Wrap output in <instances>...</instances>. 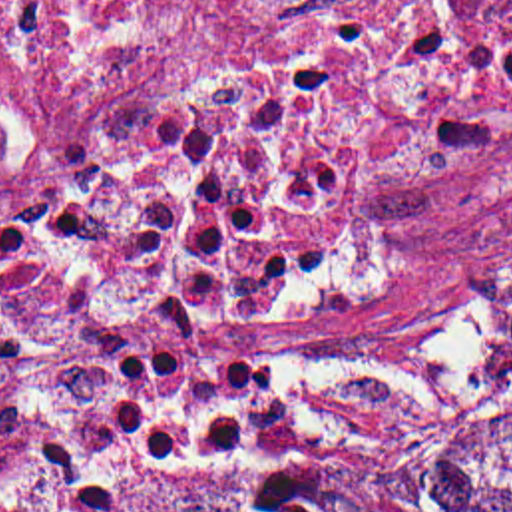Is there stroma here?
Returning <instances> with one entry per match:
<instances>
[{"label":"stroma","instance_id":"35a3bbf8","mask_svg":"<svg viewBox=\"0 0 512 512\" xmlns=\"http://www.w3.org/2000/svg\"><path fill=\"white\" fill-rule=\"evenodd\" d=\"M37 195L151 201L214 221L208 207L123 185H37L0 203V213ZM238 296L246 314L272 318L278 338L282 412L274 430L168 458L111 512L129 511L202 458L382 454L463 434L512 408V364L487 344L512 304V231L497 209L376 227L316 288L294 296L238 288Z\"/></svg>","mask_w":512,"mask_h":512}]
</instances>
